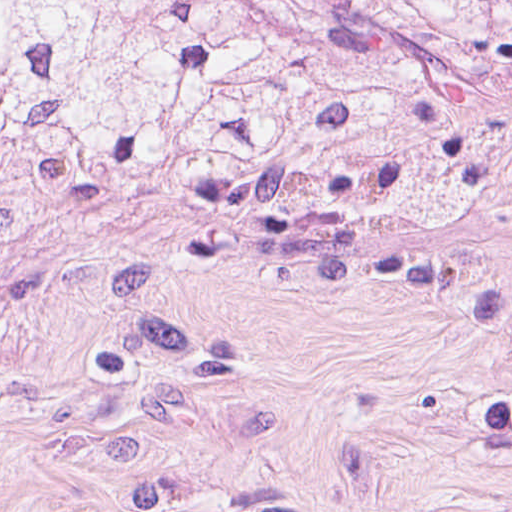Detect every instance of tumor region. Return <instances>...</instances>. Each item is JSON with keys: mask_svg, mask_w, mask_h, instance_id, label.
Here are the masks:
<instances>
[{"mask_svg": "<svg viewBox=\"0 0 512 512\" xmlns=\"http://www.w3.org/2000/svg\"><path fill=\"white\" fill-rule=\"evenodd\" d=\"M145 209L262 253L512 242V0H0V241Z\"/></svg>", "mask_w": 512, "mask_h": 512, "instance_id": "e687c5a6", "label": "tumor region"}]
</instances>
